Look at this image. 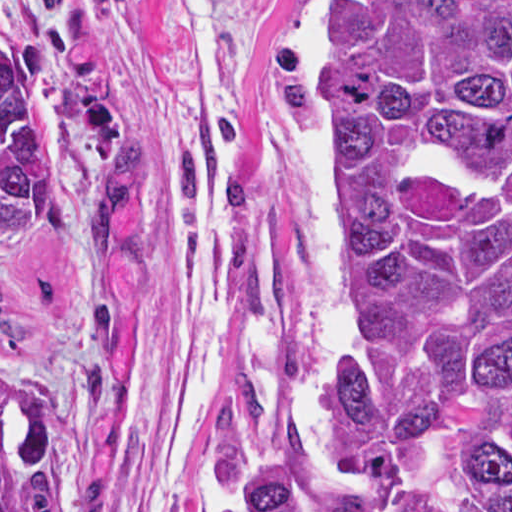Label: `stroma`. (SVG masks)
<instances>
[{
	"label": "stroma",
	"instance_id": "obj_1",
	"mask_svg": "<svg viewBox=\"0 0 512 512\" xmlns=\"http://www.w3.org/2000/svg\"><path fill=\"white\" fill-rule=\"evenodd\" d=\"M325 1L0 0L54 178L0 250V358L98 376L63 512H224L305 438L343 269Z\"/></svg>",
	"mask_w": 512,
	"mask_h": 512
}]
</instances>
